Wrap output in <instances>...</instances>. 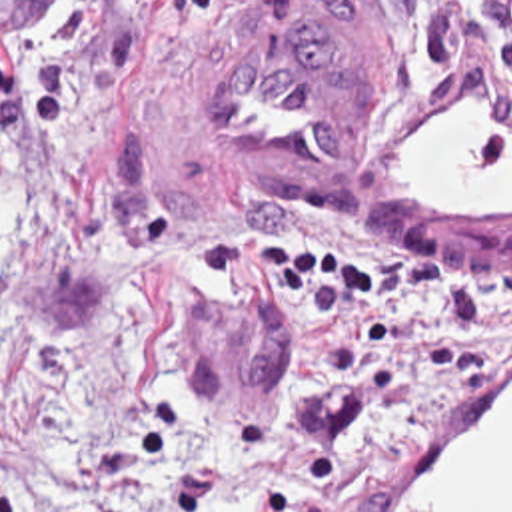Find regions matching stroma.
<instances>
[{
	"instance_id": "1",
	"label": "stroma",
	"mask_w": 512,
	"mask_h": 512,
	"mask_svg": "<svg viewBox=\"0 0 512 512\" xmlns=\"http://www.w3.org/2000/svg\"><path fill=\"white\" fill-rule=\"evenodd\" d=\"M72 0H0V72L52 50ZM481 90L487 34L431 76L345 0H206L146 18L128 94L66 144L0 114L20 146V234L0 270V425H34L84 369L100 315L152 285L200 325V391L230 421L280 433L304 357L322 351L401 397L413 437L373 469L262 497L256 512H363L425 433L512 379V321L461 371L431 375L357 347L337 301L186 293L194 250L248 234H369L441 266L512 258V218H435L383 198L389 140Z\"/></svg>"
}]
</instances>
